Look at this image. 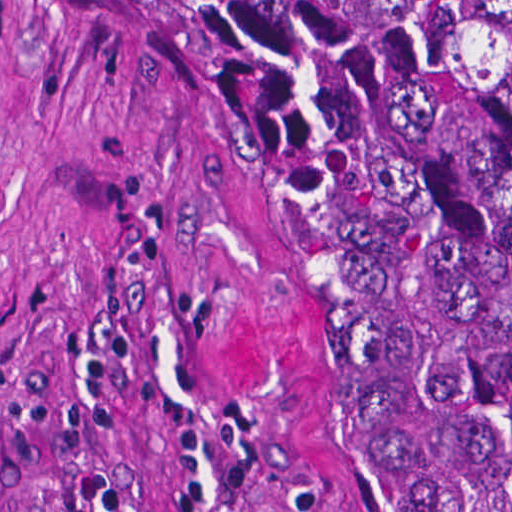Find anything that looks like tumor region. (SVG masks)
<instances>
[{"label":"tumor region","instance_id":"tumor-region-1","mask_svg":"<svg viewBox=\"0 0 512 512\" xmlns=\"http://www.w3.org/2000/svg\"><path fill=\"white\" fill-rule=\"evenodd\" d=\"M333 232L415 512H512V0H125Z\"/></svg>","mask_w":512,"mask_h":512}]
</instances>
